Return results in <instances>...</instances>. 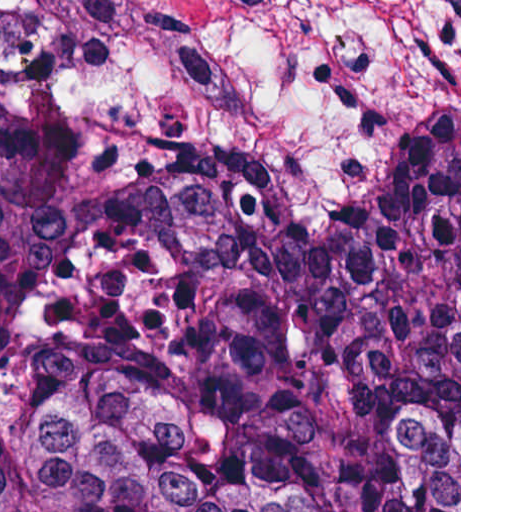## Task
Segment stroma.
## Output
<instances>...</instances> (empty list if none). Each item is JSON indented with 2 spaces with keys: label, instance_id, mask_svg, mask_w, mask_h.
<instances>
[{
  "label": "stroma",
  "instance_id": "35a3bbf8",
  "mask_svg": "<svg viewBox=\"0 0 512 512\" xmlns=\"http://www.w3.org/2000/svg\"><path fill=\"white\" fill-rule=\"evenodd\" d=\"M0 75L94 199L210 168L353 281L441 158L459 250L461 0H0Z\"/></svg>",
  "mask_w": 512,
  "mask_h": 512
}]
</instances>
